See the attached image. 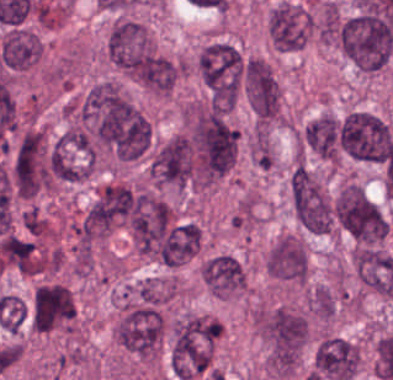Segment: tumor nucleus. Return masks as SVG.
Instances as JSON below:
<instances>
[{
    "mask_svg": "<svg viewBox=\"0 0 393 380\" xmlns=\"http://www.w3.org/2000/svg\"><path fill=\"white\" fill-rule=\"evenodd\" d=\"M302 148L329 164L340 159L339 118L330 111H321L307 120L297 133Z\"/></svg>",
    "mask_w": 393,
    "mask_h": 380,
    "instance_id": "12",
    "label": "tumor nucleus"
},
{
    "mask_svg": "<svg viewBox=\"0 0 393 380\" xmlns=\"http://www.w3.org/2000/svg\"><path fill=\"white\" fill-rule=\"evenodd\" d=\"M340 151L358 161L384 162L393 146V129L378 112L348 108L339 116Z\"/></svg>",
    "mask_w": 393,
    "mask_h": 380,
    "instance_id": "3",
    "label": "tumor nucleus"
},
{
    "mask_svg": "<svg viewBox=\"0 0 393 380\" xmlns=\"http://www.w3.org/2000/svg\"><path fill=\"white\" fill-rule=\"evenodd\" d=\"M359 362L357 344L350 340L324 335L314 349L312 369L321 377H354Z\"/></svg>",
    "mask_w": 393,
    "mask_h": 380,
    "instance_id": "11",
    "label": "tumor nucleus"
},
{
    "mask_svg": "<svg viewBox=\"0 0 393 380\" xmlns=\"http://www.w3.org/2000/svg\"><path fill=\"white\" fill-rule=\"evenodd\" d=\"M333 215L338 228L360 244H379L388 233L380 207L354 182L339 186L333 199Z\"/></svg>",
    "mask_w": 393,
    "mask_h": 380,
    "instance_id": "6",
    "label": "tumor nucleus"
},
{
    "mask_svg": "<svg viewBox=\"0 0 393 380\" xmlns=\"http://www.w3.org/2000/svg\"><path fill=\"white\" fill-rule=\"evenodd\" d=\"M197 76L227 109L238 101L244 78V56L232 44L212 41L203 46L196 57Z\"/></svg>",
    "mask_w": 393,
    "mask_h": 380,
    "instance_id": "4",
    "label": "tumor nucleus"
},
{
    "mask_svg": "<svg viewBox=\"0 0 393 380\" xmlns=\"http://www.w3.org/2000/svg\"><path fill=\"white\" fill-rule=\"evenodd\" d=\"M305 304L317 319L330 320L336 308V296L330 286L317 285L307 292Z\"/></svg>",
    "mask_w": 393,
    "mask_h": 380,
    "instance_id": "13",
    "label": "tumor nucleus"
},
{
    "mask_svg": "<svg viewBox=\"0 0 393 380\" xmlns=\"http://www.w3.org/2000/svg\"><path fill=\"white\" fill-rule=\"evenodd\" d=\"M293 218L303 230L317 234L332 231L334 217L321 177L301 163H293L286 180Z\"/></svg>",
    "mask_w": 393,
    "mask_h": 380,
    "instance_id": "5",
    "label": "tumor nucleus"
},
{
    "mask_svg": "<svg viewBox=\"0 0 393 380\" xmlns=\"http://www.w3.org/2000/svg\"><path fill=\"white\" fill-rule=\"evenodd\" d=\"M190 182L209 188L236 163L238 134L220 111L195 110L186 116Z\"/></svg>",
    "mask_w": 393,
    "mask_h": 380,
    "instance_id": "1",
    "label": "tumor nucleus"
},
{
    "mask_svg": "<svg viewBox=\"0 0 393 380\" xmlns=\"http://www.w3.org/2000/svg\"><path fill=\"white\" fill-rule=\"evenodd\" d=\"M201 282L208 293L221 298H235L246 293L245 270L229 251H216L199 264Z\"/></svg>",
    "mask_w": 393,
    "mask_h": 380,
    "instance_id": "10",
    "label": "tumor nucleus"
},
{
    "mask_svg": "<svg viewBox=\"0 0 393 380\" xmlns=\"http://www.w3.org/2000/svg\"><path fill=\"white\" fill-rule=\"evenodd\" d=\"M309 31V11L287 0L272 5L265 19L267 41L277 51L299 49L306 43Z\"/></svg>",
    "mask_w": 393,
    "mask_h": 380,
    "instance_id": "8",
    "label": "tumor nucleus"
},
{
    "mask_svg": "<svg viewBox=\"0 0 393 380\" xmlns=\"http://www.w3.org/2000/svg\"><path fill=\"white\" fill-rule=\"evenodd\" d=\"M149 180L183 192L190 182V148L185 135L174 133L154 144L148 157Z\"/></svg>",
    "mask_w": 393,
    "mask_h": 380,
    "instance_id": "7",
    "label": "tumor nucleus"
},
{
    "mask_svg": "<svg viewBox=\"0 0 393 380\" xmlns=\"http://www.w3.org/2000/svg\"><path fill=\"white\" fill-rule=\"evenodd\" d=\"M250 324L263 368H294L306 341L307 321L296 309L254 306Z\"/></svg>",
    "mask_w": 393,
    "mask_h": 380,
    "instance_id": "2",
    "label": "tumor nucleus"
},
{
    "mask_svg": "<svg viewBox=\"0 0 393 380\" xmlns=\"http://www.w3.org/2000/svg\"><path fill=\"white\" fill-rule=\"evenodd\" d=\"M263 270L275 282L301 286L307 274L306 250L301 239L288 233L277 235L265 254Z\"/></svg>",
    "mask_w": 393,
    "mask_h": 380,
    "instance_id": "9",
    "label": "tumor nucleus"
}]
</instances>
